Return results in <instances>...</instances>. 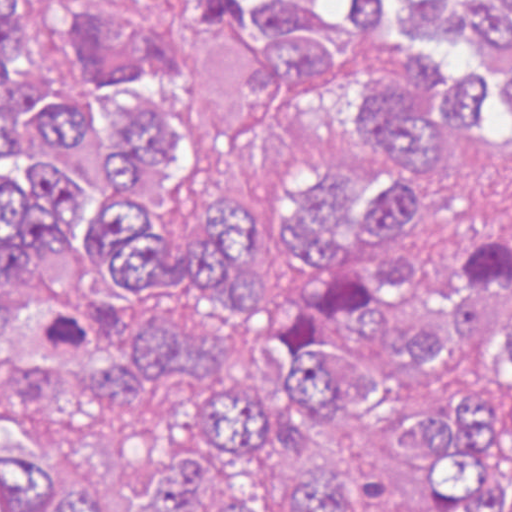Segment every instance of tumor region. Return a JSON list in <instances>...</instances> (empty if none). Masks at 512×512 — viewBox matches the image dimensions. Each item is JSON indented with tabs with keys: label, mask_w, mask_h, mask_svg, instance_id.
Segmentation results:
<instances>
[{
	"label": "tumor region",
	"mask_w": 512,
	"mask_h": 512,
	"mask_svg": "<svg viewBox=\"0 0 512 512\" xmlns=\"http://www.w3.org/2000/svg\"><path fill=\"white\" fill-rule=\"evenodd\" d=\"M190 25L260 66L261 108L209 127L156 87L168 48L88 5V69L53 90L25 0H0V365L50 367L84 414L144 418L187 383V441L139 501L83 505L34 449L0 443V512H361L341 479L299 473L272 505L224 501L203 454L249 469L293 411L380 426L398 387L439 383L452 346L512 365V225L411 248L399 173L316 161L285 189L293 273L254 279L247 216L164 236L156 211L199 147H247L323 108L405 170L512 135V0H177ZM441 512H512V403L448 399L401 442Z\"/></svg>",
	"instance_id": "obj_1"
}]
</instances>
